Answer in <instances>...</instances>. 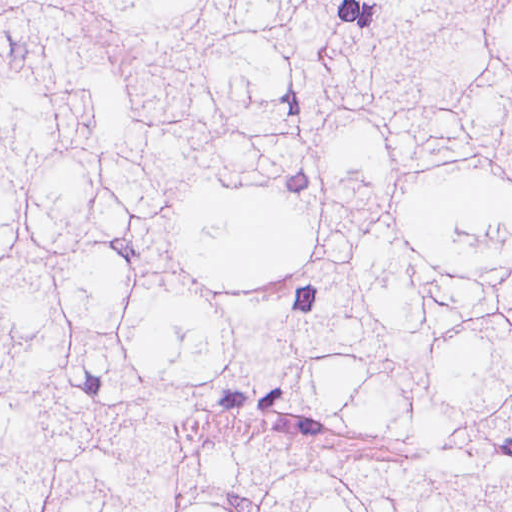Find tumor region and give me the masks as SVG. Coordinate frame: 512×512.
<instances>
[{"mask_svg":"<svg viewBox=\"0 0 512 512\" xmlns=\"http://www.w3.org/2000/svg\"><path fill=\"white\" fill-rule=\"evenodd\" d=\"M0 512H512V0H0Z\"/></svg>","mask_w":512,"mask_h":512,"instance_id":"tumor-region-1","label":"tumor region"}]
</instances>
